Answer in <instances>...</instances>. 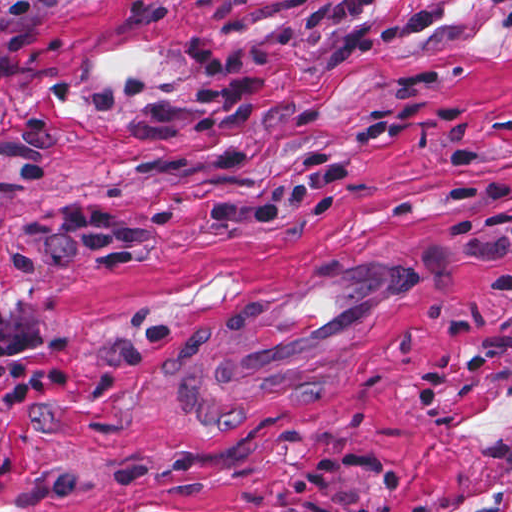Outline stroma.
Here are the masks:
<instances>
[{"label":"stroma","mask_w":512,"mask_h":512,"mask_svg":"<svg viewBox=\"0 0 512 512\" xmlns=\"http://www.w3.org/2000/svg\"><path fill=\"white\" fill-rule=\"evenodd\" d=\"M309 1L0 0V309L69 370L67 401L0 431V512H512V299L478 289L512 261L447 229L512 225V0L375 3L377 28L436 21L338 67ZM200 40L273 51L243 171L210 131L140 143L138 104L88 112L130 76L186 97ZM436 100L462 118L374 143L330 214L204 221L341 154L368 107ZM75 204L156 239L114 271H12L28 224Z\"/></svg>","instance_id":"stroma-1"}]
</instances>
